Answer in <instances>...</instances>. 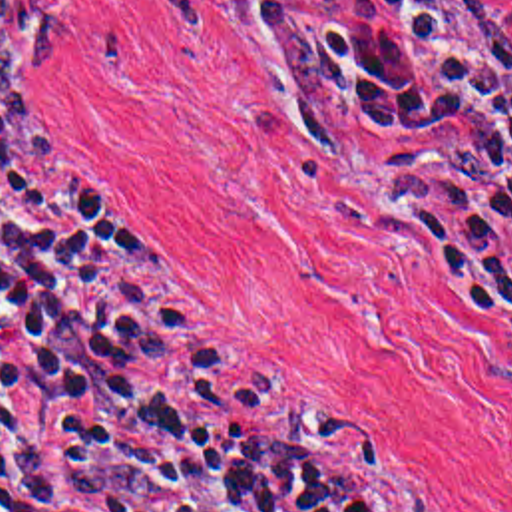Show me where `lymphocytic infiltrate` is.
<instances>
[{
	"instance_id": "1",
	"label": "lymphocytic infiltrate",
	"mask_w": 512,
	"mask_h": 512,
	"mask_svg": "<svg viewBox=\"0 0 512 512\" xmlns=\"http://www.w3.org/2000/svg\"><path fill=\"white\" fill-rule=\"evenodd\" d=\"M304 143L442 151L414 230L512 342V95L458 0H254ZM0 509L424 512L298 392L193 332L145 250L0 131Z\"/></svg>"
}]
</instances>
